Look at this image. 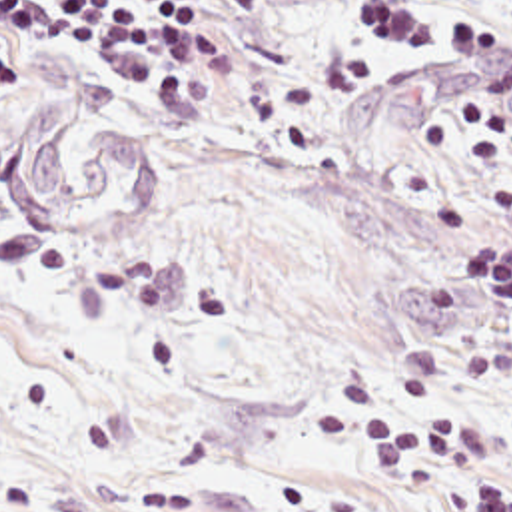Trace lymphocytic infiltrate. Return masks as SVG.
Wrapping results in <instances>:
<instances>
[{
    "label": "lymphocytic infiltrate",
    "mask_w": 512,
    "mask_h": 512,
    "mask_svg": "<svg viewBox=\"0 0 512 512\" xmlns=\"http://www.w3.org/2000/svg\"><path fill=\"white\" fill-rule=\"evenodd\" d=\"M447 17V55L435 75L475 105L512 115V53L469 0H423ZM511 5L512 0H499ZM262 0H0V83L64 75L92 59L126 63L152 85L188 83L218 73L254 35ZM409 43L407 27L387 15ZM449 279L512 312V243L483 241L459 251ZM322 438L359 436L379 474L425 494L469 482L473 494L455 512H512V486L475 464L467 416L413 424L387 412L381 392L345 382L316 416ZM32 476L0 504L26 512L38 492Z\"/></svg>",
    "instance_id": "obj_1"
}]
</instances>
